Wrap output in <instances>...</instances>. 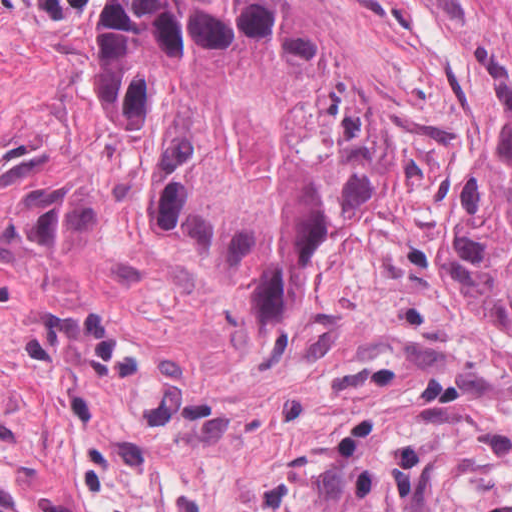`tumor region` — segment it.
Returning <instances> with one entry per match:
<instances>
[{
	"label": "tumor region",
	"instance_id": "1",
	"mask_svg": "<svg viewBox=\"0 0 512 512\" xmlns=\"http://www.w3.org/2000/svg\"><path fill=\"white\" fill-rule=\"evenodd\" d=\"M97 66L103 96L114 112L122 130L140 131L98 57ZM152 212L178 236L208 249L161 167L152 179Z\"/></svg>",
	"mask_w": 512,
	"mask_h": 512
}]
</instances>
